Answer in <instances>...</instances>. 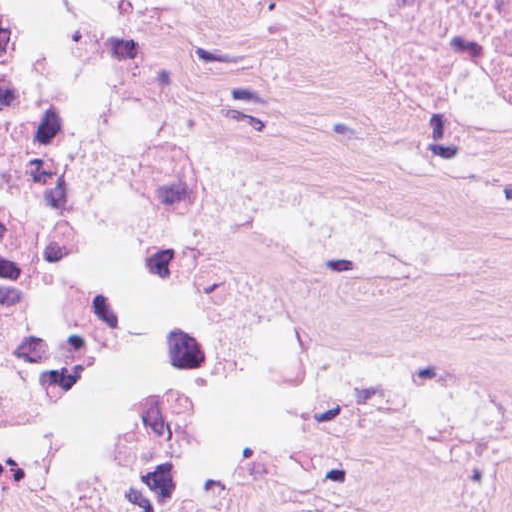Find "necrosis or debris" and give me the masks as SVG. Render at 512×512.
Returning <instances> with one entry per match:
<instances>
[{"label":"necrosis or debris","instance_id":"necrosis-or-debris-1","mask_svg":"<svg viewBox=\"0 0 512 512\" xmlns=\"http://www.w3.org/2000/svg\"><path fill=\"white\" fill-rule=\"evenodd\" d=\"M345 1L512 163V0ZM171 144L84 0H0V512H34L55 474L160 470L135 241L163 223Z\"/></svg>","mask_w":512,"mask_h":512}]
</instances>
